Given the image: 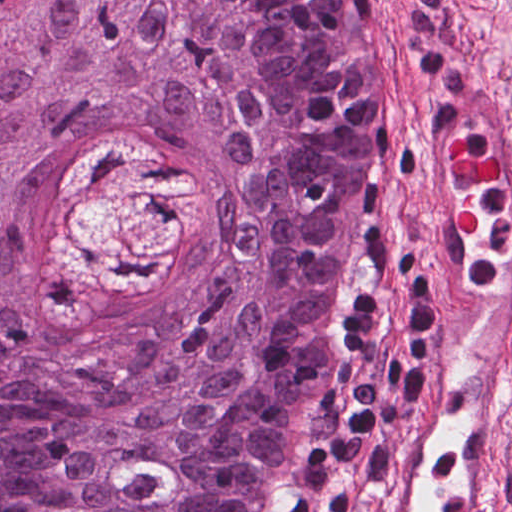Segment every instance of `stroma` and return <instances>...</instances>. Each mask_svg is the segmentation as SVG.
<instances>
[{"instance_id": "stroma-1", "label": "stroma", "mask_w": 512, "mask_h": 512, "mask_svg": "<svg viewBox=\"0 0 512 512\" xmlns=\"http://www.w3.org/2000/svg\"><path fill=\"white\" fill-rule=\"evenodd\" d=\"M379 31L374 70L384 106L394 107V149L382 181L386 193L340 304L288 450L283 484L333 382L338 338L362 288L381 263L407 261L413 175L430 109L460 75L480 70L512 97V0H372ZM505 512H512V433L502 469ZM281 494V493H280Z\"/></svg>"}]
</instances>
